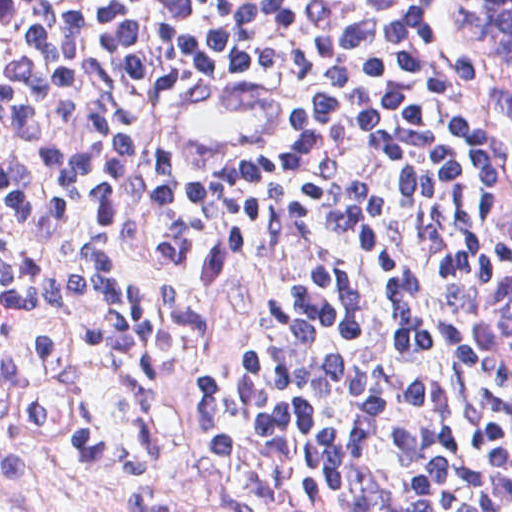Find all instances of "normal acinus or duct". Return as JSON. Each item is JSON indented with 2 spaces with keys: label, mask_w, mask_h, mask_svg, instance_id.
<instances>
[{
  "label": "normal acinus or duct",
  "mask_w": 512,
  "mask_h": 512,
  "mask_svg": "<svg viewBox=\"0 0 512 512\" xmlns=\"http://www.w3.org/2000/svg\"><path fill=\"white\" fill-rule=\"evenodd\" d=\"M451 19L459 33L512 81V0H452ZM501 337L512 348V288L503 295Z\"/></svg>",
  "instance_id": "30e58d81"
}]
</instances>
